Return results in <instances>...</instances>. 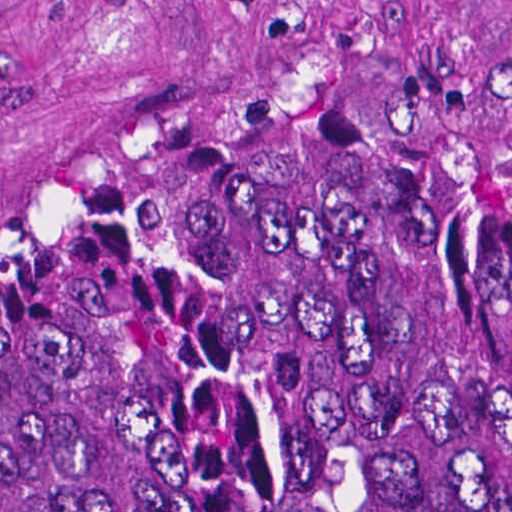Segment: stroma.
Listing matches in <instances>:
<instances>
[{"label": "stroma", "mask_w": 512, "mask_h": 512, "mask_svg": "<svg viewBox=\"0 0 512 512\" xmlns=\"http://www.w3.org/2000/svg\"><path fill=\"white\" fill-rule=\"evenodd\" d=\"M348 111L512 175V0H0V272L214 119Z\"/></svg>", "instance_id": "1"}]
</instances>
